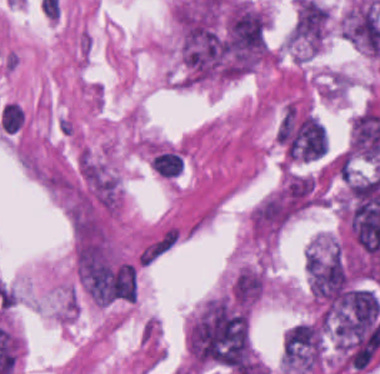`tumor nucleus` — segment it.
I'll list each match as a JSON object with an SVG mask.
<instances>
[{
  "label": "tumor nucleus",
  "mask_w": 380,
  "mask_h": 374,
  "mask_svg": "<svg viewBox=\"0 0 380 374\" xmlns=\"http://www.w3.org/2000/svg\"><path fill=\"white\" fill-rule=\"evenodd\" d=\"M323 359L320 336L307 320L296 323L284 336L282 365L290 373L320 369Z\"/></svg>",
  "instance_id": "5ab6c2c4"
},
{
  "label": "tumor nucleus",
  "mask_w": 380,
  "mask_h": 374,
  "mask_svg": "<svg viewBox=\"0 0 380 374\" xmlns=\"http://www.w3.org/2000/svg\"><path fill=\"white\" fill-rule=\"evenodd\" d=\"M77 167L81 195L104 211L117 212L119 187L105 162L82 149Z\"/></svg>",
  "instance_id": "8643909e"
},
{
  "label": "tumor nucleus",
  "mask_w": 380,
  "mask_h": 374,
  "mask_svg": "<svg viewBox=\"0 0 380 374\" xmlns=\"http://www.w3.org/2000/svg\"><path fill=\"white\" fill-rule=\"evenodd\" d=\"M225 44L230 60L270 61V16L252 1L240 0L227 14Z\"/></svg>",
  "instance_id": "2f306a5c"
}]
</instances>
